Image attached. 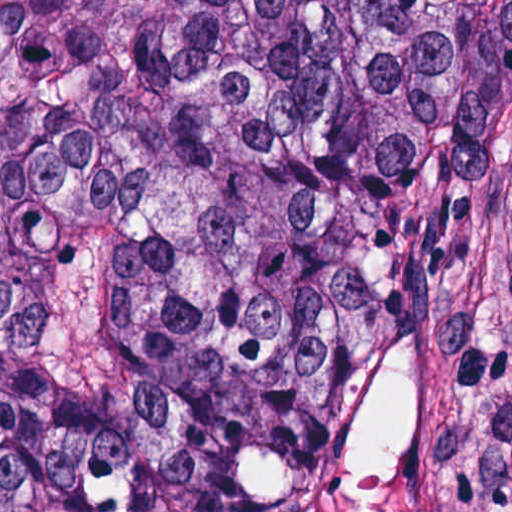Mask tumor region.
<instances>
[{
  "instance_id": "obj_1",
  "label": "tumor region",
  "mask_w": 512,
  "mask_h": 512,
  "mask_svg": "<svg viewBox=\"0 0 512 512\" xmlns=\"http://www.w3.org/2000/svg\"><path fill=\"white\" fill-rule=\"evenodd\" d=\"M0 512H512V0H0Z\"/></svg>"
}]
</instances>
